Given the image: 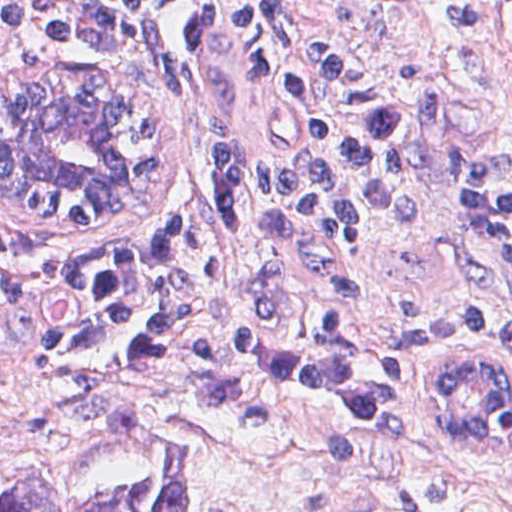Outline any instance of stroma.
<instances>
[{"label": "stroma", "mask_w": 512, "mask_h": 512, "mask_svg": "<svg viewBox=\"0 0 512 512\" xmlns=\"http://www.w3.org/2000/svg\"><path fill=\"white\" fill-rule=\"evenodd\" d=\"M338 58L403 121V168L366 202L339 249L231 225L216 229L220 323L329 354L398 385L372 425L289 438L239 428L173 395L70 372L16 349L0 319V478L91 453L113 408L132 403L190 455V512H512V450L466 461L431 441L420 373L394 358L405 326L449 311H512V255L471 243L448 152L492 143L512 175V0H405L401 23L367 36L303 0ZM34 67L68 73L107 102L126 138L110 213L71 214L0 183V259L123 235L181 231L215 168L278 147L265 84L233 0H209L184 32L96 71L0 33L5 90Z\"/></svg>", "instance_id": "obj_1"}]
</instances>
